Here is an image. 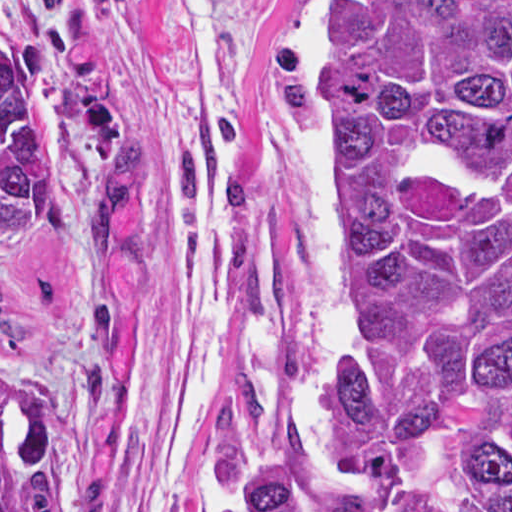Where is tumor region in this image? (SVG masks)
Instances as JSON below:
<instances>
[{
  "mask_svg": "<svg viewBox=\"0 0 512 512\" xmlns=\"http://www.w3.org/2000/svg\"><path fill=\"white\" fill-rule=\"evenodd\" d=\"M320 120L329 360L224 512H512V1H325ZM52 202L0 74V250ZM97 380L0 358V512H63Z\"/></svg>",
  "mask_w": 512,
  "mask_h": 512,
  "instance_id": "tumor-region-1",
  "label": "tumor region"
}]
</instances>
